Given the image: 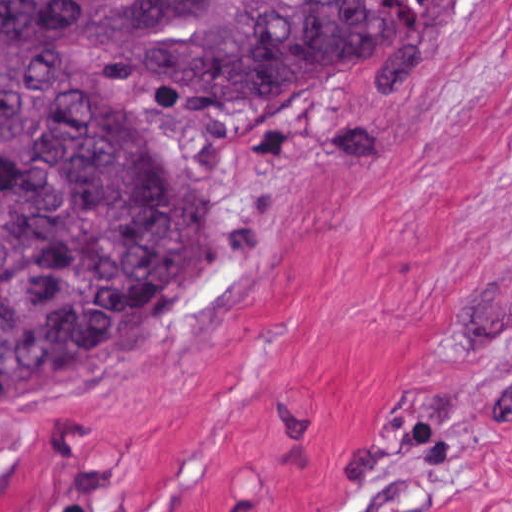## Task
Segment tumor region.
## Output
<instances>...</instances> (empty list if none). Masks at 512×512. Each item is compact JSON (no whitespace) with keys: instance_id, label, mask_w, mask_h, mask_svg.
<instances>
[{"instance_id":"e687c5a6","label":"tumor region","mask_w":512,"mask_h":512,"mask_svg":"<svg viewBox=\"0 0 512 512\" xmlns=\"http://www.w3.org/2000/svg\"><path fill=\"white\" fill-rule=\"evenodd\" d=\"M472 0H0V417L145 379L191 223L94 100H230L407 58Z\"/></svg>"}]
</instances>
